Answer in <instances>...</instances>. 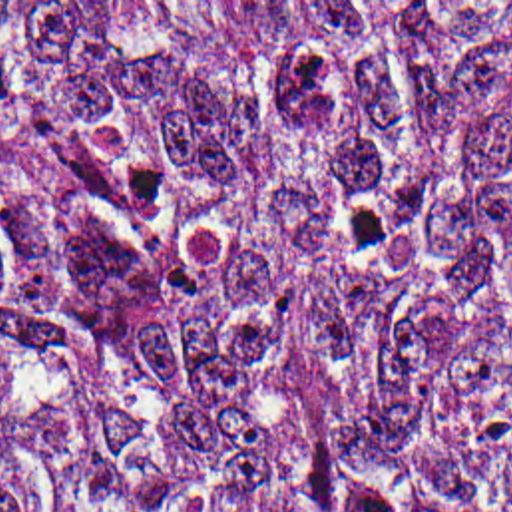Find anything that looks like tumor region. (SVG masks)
Masks as SVG:
<instances>
[{"label": "tumor region", "mask_w": 512, "mask_h": 512, "mask_svg": "<svg viewBox=\"0 0 512 512\" xmlns=\"http://www.w3.org/2000/svg\"><path fill=\"white\" fill-rule=\"evenodd\" d=\"M0 512H512V2H0Z\"/></svg>", "instance_id": "1"}]
</instances>
